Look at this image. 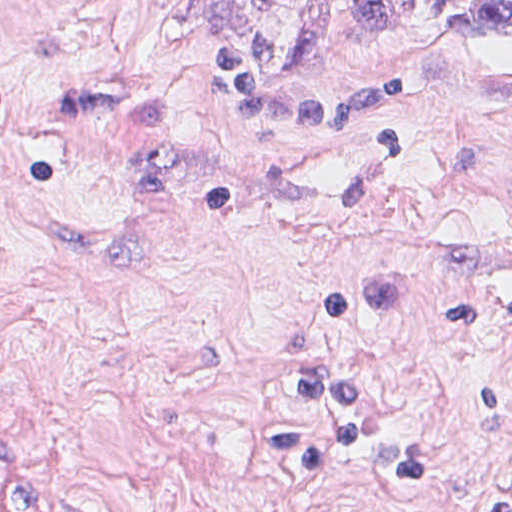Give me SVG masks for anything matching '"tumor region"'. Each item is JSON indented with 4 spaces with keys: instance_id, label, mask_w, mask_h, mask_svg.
<instances>
[{
    "instance_id": "tumor-region-1",
    "label": "tumor region",
    "mask_w": 512,
    "mask_h": 512,
    "mask_svg": "<svg viewBox=\"0 0 512 512\" xmlns=\"http://www.w3.org/2000/svg\"><path fill=\"white\" fill-rule=\"evenodd\" d=\"M445 17L491 33H512V0H444Z\"/></svg>"
}]
</instances>
